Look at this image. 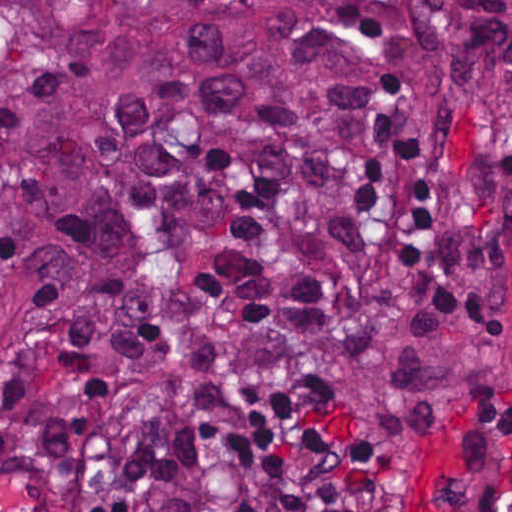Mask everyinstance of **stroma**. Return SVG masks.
Returning <instances> with one entry per match:
<instances>
[{"mask_svg": "<svg viewBox=\"0 0 512 512\" xmlns=\"http://www.w3.org/2000/svg\"><path fill=\"white\" fill-rule=\"evenodd\" d=\"M388 74L408 90L388 106L390 117L375 118L393 100L381 81ZM408 134H440L460 160L475 242L512 309V217L493 205L494 189L512 185V120L491 89L456 77L429 44L378 62L366 83L363 130L325 166L289 185L346 170L361 144ZM259 185L270 184L241 158L175 188L135 223L91 234L1 357L0 389L125 250ZM392 512H512V376H459L435 394Z\"/></svg>", "mask_w": 512, "mask_h": 512, "instance_id": "1", "label": "stroma"}]
</instances>
